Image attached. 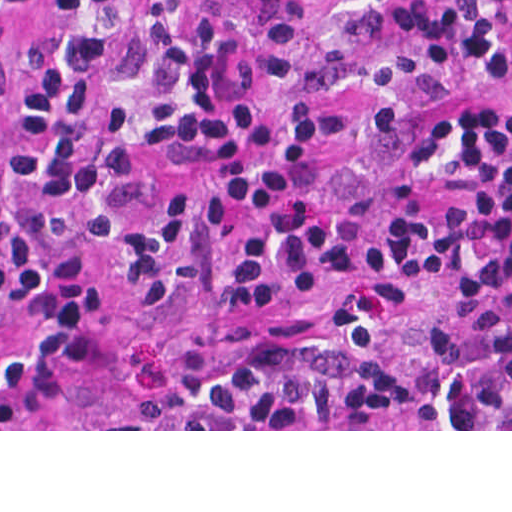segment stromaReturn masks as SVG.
<instances>
[{
    "mask_svg": "<svg viewBox=\"0 0 512 512\" xmlns=\"http://www.w3.org/2000/svg\"><path fill=\"white\" fill-rule=\"evenodd\" d=\"M299 23L308 46L295 96L330 99L346 109L349 122L323 174V201L338 209L376 201L383 150L374 100L391 39L361 23L344 0H256L236 33L203 24L194 11L182 20V41L192 59L233 90L245 122L261 130L273 119L270 36ZM38 39L28 27L0 24V267L8 248L5 133ZM489 87L510 84L499 67L459 43L456 72L419 123H434L447 143L428 207L434 250L437 221L453 192L449 153L456 123L468 100ZM158 170L176 197L182 226L176 289L159 295L136 290L115 260H100L94 311L37 381L0 402V431H512L424 429L415 371L419 345L433 321L459 301L435 255L431 279L400 319L387 350L400 405L379 429H189L181 421V401L201 381L325 330L336 316L327 301L313 298L242 314L219 308L206 295L213 246L203 189L193 171Z\"/></svg>",
    "mask_w": 512,
    "mask_h": 512,
    "instance_id": "stroma-1",
    "label": "stroma"
}]
</instances>
